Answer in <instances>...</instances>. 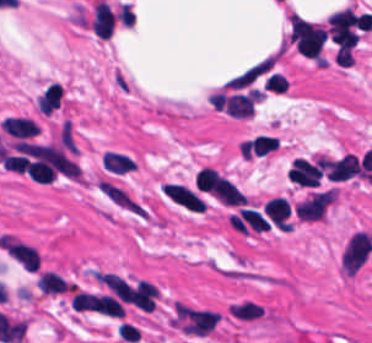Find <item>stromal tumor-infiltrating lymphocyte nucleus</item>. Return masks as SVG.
Here are the masks:
<instances>
[{"label":"stromal tumor-infiltrating lymphocyte nucleus","mask_w":372,"mask_h":343,"mask_svg":"<svg viewBox=\"0 0 372 343\" xmlns=\"http://www.w3.org/2000/svg\"><path fill=\"white\" fill-rule=\"evenodd\" d=\"M101 167L112 173H126L136 168V163L127 155L105 151L101 154Z\"/></svg>","instance_id":"stromal-tumor-infiltrating-lymphocyte-nucleus-4"},{"label":"stromal tumor-infiltrating lymphocyte nucleus","mask_w":372,"mask_h":343,"mask_svg":"<svg viewBox=\"0 0 372 343\" xmlns=\"http://www.w3.org/2000/svg\"><path fill=\"white\" fill-rule=\"evenodd\" d=\"M372 250V236L364 230H357L349 236L343 247L341 264L348 275H355L369 257Z\"/></svg>","instance_id":"stromal-tumor-infiltrating-lymphocyte-nucleus-1"},{"label":"stromal tumor-infiltrating lymphocyte nucleus","mask_w":372,"mask_h":343,"mask_svg":"<svg viewBox=\"0 0 372 343\" xmlns=\"http://www.w3.org/2000/svg\"><path fill=\"white\" fill-rule=\"evenodd\" d=\"M1 128L9 136L17 139H27L39 134L36 122L21 116H8L2 120Z\"/></svg>","instance_id":"stromal-tumor-infiltrating-lymphocyte-nucleus-2"},{"label":"stromal tumor-infiltrating lymphocyte nucleus","mask_w":372,"mask_h":343,"mask_svg":"<svg viewBox=\"0 0 372 343\" xmlns=\"http://www.w3.org/2000/svg\"><path fill=\"white\" fill-rule=\"evenodd\" d=\"M36 283L39 290L49 295L70 291V283L61 274L50 270H42Z\"/></svg>","instance_id":"stromal-tumor-infiltrating-lymphocyte-nucleus-3"}]
</instances>
